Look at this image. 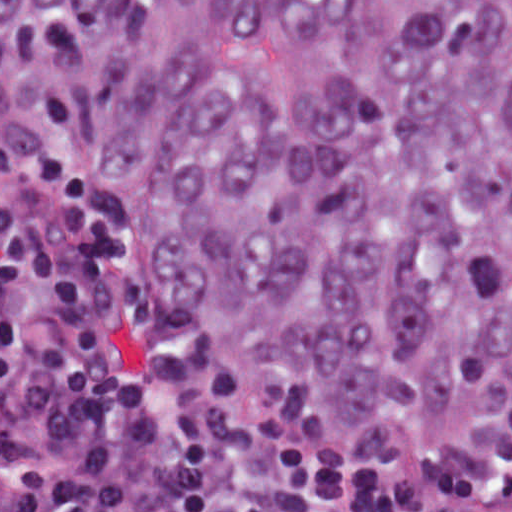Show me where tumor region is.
<instances>
[{
    "label": "tumor region",
    "instance_id": "obj_1",
    "mask_svg": "<svg viewBox=\"0 0 512 512\" xmlns=\"http://www.w3.org/2000/svg\"><path fill=\"white\" fill-rule=\"evenodd\" d=\"M0 62L148 273L333 441L512 408V0H0Z\"/></svg>",
    "mask_w": 512,
    "mask_h": 512
}]
</instances>
